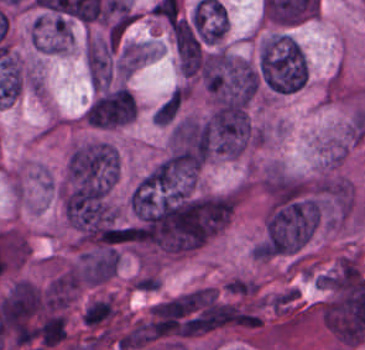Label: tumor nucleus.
<instances>
[{
  "label": "tumor nucleus",
  "mask_w": 365,
  "mask_h": 350,
  "mask_svg": "<svg viewBox=\"0 0 365 350\" xmlns=\"http://www.w3.org/2000/svg\"><path fill=\"white\" fill-rule=\"evenodd\" d=\"M256 66L263 87L277 95L303 88L308 71L303 49L285 35L269 36L261 44Z\"/></svg>",
  "instance_id": "obj_1"
},
{
  "label": "tumor nucleus",
  "mask_w": 365,
  "mask_h": 350,
  "mask_svg": "<svg viewBox=\"0 0 365 350\" xmlns=\"http://www.w3.org/2000/svg\"><path fill=\"white\" fill-rule=\"evenodd\" d=\"M202 81L215 100L248 104L260 85L255 63L228 50L211 54L202 68Z\"/></svg>",
  "instance_id": "obj_2"
},
{
  "label": "tumor nucleus",
  "mask_w": 365,
  "mask_h": 350,
  "mask_svg": "<svg viewBox=\"0 0 365 350\" xmlns=\"http://www.w3.org/2000/svg\"><path fill=\"white\" fill-rule=\"evenodd\" d=\"M166 155L184 169L200 165L208 157L207 117L178 119L170 129Z\"/></svg>",
  "instance_id": "obj_3"
},
{
  "label": "tumor nucleus",
  "mask_w": 365,
  "mask_h": 350,
  "mask_svg": "<svg viewBox=\"0 0 365 350\" xmlns=\"http://www.w3.org/2000/svg\"><path fill=\"white\" fill-rule=\"evenodd\" d=\"M309 190L323 206L341 218L355 207V190L350 180L341 176H321Z\"/></svg>",
  "instance_id": "obj_4"
},
{
  "label": "tumor nucleus",
  "mask_w": 365,
  "mask_h": 350,
  "mask_svg": "<svg viewBox=\"0 0 365 350\" xmlns=\"http://www.w3.org/2000/svg\"><path fill=\"white\" fill-rule=\"evenodd\" d=\"M182 101L180 89H173L164 100L155 108V124L167 125L176 120Z\"/></svg>",
  "instance_id": "obj_5"
}]
</instances>
